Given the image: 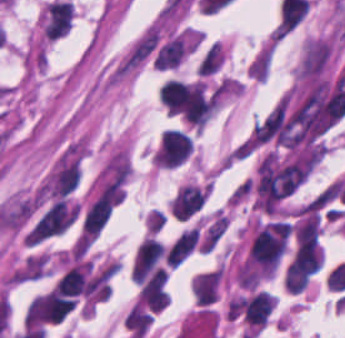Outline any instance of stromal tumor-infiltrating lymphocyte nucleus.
Returning <instances> with one entry per match:
<instances>
[{"label": "stromal tumor-infiltrating lymphocyte nucleus", "instance_id": "obj_2", "mask_svg": "<svg viewBox=\"0 0 345 338\" xmlns=\"http://www.w3.org/2000/svg\"><path fill=\"white\" fill-rule=\"evenodd\" d=\"M315 268L306 260L292 259L287 265L285 285L287 292L301 293L310 282Z\"/></svg>", "mask_w": 345, "mask_h": 338}, {"label": "stromal tumor-infiltrating lymphocyte nucleus", "instance_id": "obj_1", "mask_svg": "<svg viewBox=\"0 0 345 338\" xmlns=\"http://www.w3.org/2000/svg\"><path fill=\"white\" fill-rule=\"evenodd\" d=\"M208 195V185L196 182L182 185L171 198L170 210L173 218L191 220L200 212Z\"/></svg>", "mask_w": 345, "mask_h": 338}, {"label": "stromal tumor-infiltrating lymphocyte nucleus", "instance_id": "obj_3", "mask_svg": "<svg viewBox=\"0 0 345 338\" xmlns=\"http://www.w3.org/2000/svg\"><path fill=\"white\" fill-rule=\"evenodd\" d=\"M223 61V45L215 41L203 55L197 74L209 75L220 68Z\"/></svg>", "mask_w": 345, "mask_h": 338}]
</instances>
